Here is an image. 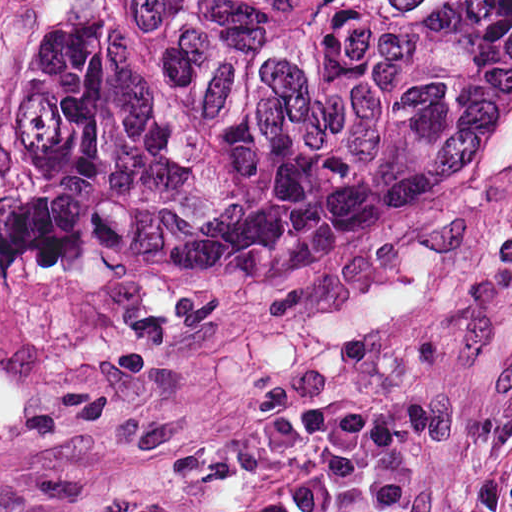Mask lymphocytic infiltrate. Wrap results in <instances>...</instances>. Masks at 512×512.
Masks as SVG:
<instances>
[{"label":"lymphocytic infiltrate","mask_w":512,"mask_h":512,"mask_svg":"<svg viewBox=\"0 0 512 512\" xmlns=\"http://www.w3.org/2000/svg\"><path fill=\"white\" fill-rule=\"evenodd\" d=\"M512 365L489 430L442 512H512ZM291 458L248 506L205 512H411L426 458L403 410L334 391L299 393L129 473L0 483V512H172L245 463Z\"/></svg>","instance_id":"1"}]
</instances>
